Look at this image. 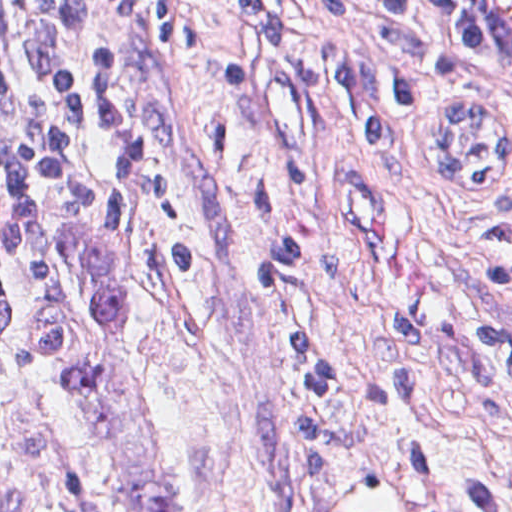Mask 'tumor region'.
<instances>
[{"label":"tumor region","mask_w":512,"mask_h":512,"mask_svg":"<svg viewBox=\"0 0 512 512\" xmlns=\"http://www.w3.org/2000/svg\"><path fill=\"white\" fill-rule=\"evenodd\" d=\"M466 17V16H465ZM467 22L469 45L481 57L496 61ZM86 248L96 283L91 305L97 316L105 320L109 330L102 347L86 359L75 362L62 378L61 390L81 392L97 383L112 367L119 337L126 328V288L118 264L107 244L103 226L91 223L86 234Z\"/></svg>","instance_id":"e687c5a6"}]
</instances>
